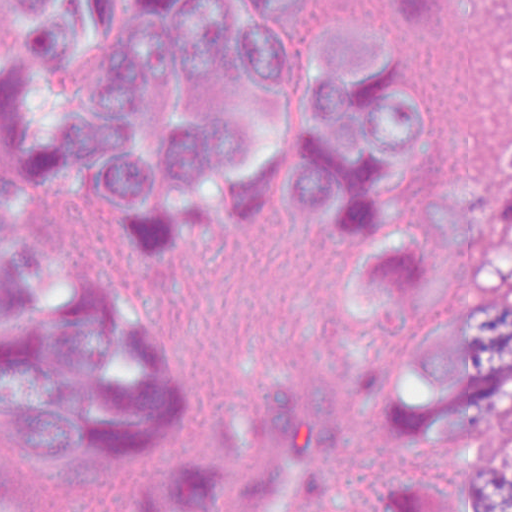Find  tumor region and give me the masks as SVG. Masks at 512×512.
<instances>
[{"instance_id":"1","label":"tumor region","mask_w":512,"mask_h":512,"mask_svg":"<svg viewBox=\"0 0 512 512\" xmlns=\"http://www.w3.org/2000/svg\"><path fill=\"white\" fill-rule=\"evenodd\" d=\"M377 305L402 316L385 375L410 430L492 401L512 420V231H451L366 253ZM402 512H512V475L475 469L464 489H393Z\"/></svg>"}]
</instances>
